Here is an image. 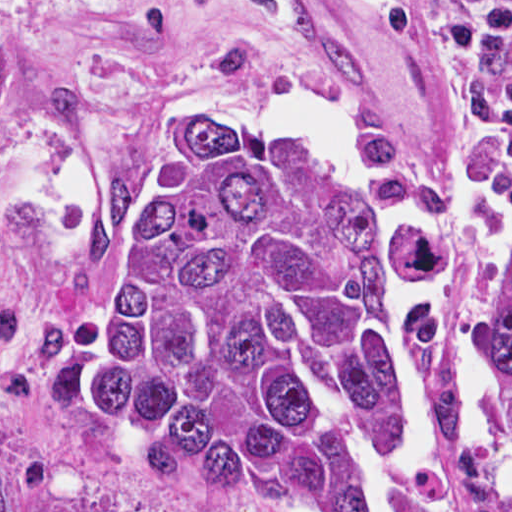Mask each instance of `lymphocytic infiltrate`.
Instances as JSON below:
<instances>
[{
    "label": "lymphocytic infiltrate",
    "instance_id": "f902f5d3",
    "mask_svg": "<svg viewBox=\"0 0 512 512\" xmlns=\"http://www.w3.org/2000/svg\"><path fill=\"white\" fill-rule=\"evenodd\" d=\"M413 30L462 95L469 127L512 132V0H364Z\"/></svg>",
    "mask_w": 512,
    "mask_h": 512
}]
</instances>
